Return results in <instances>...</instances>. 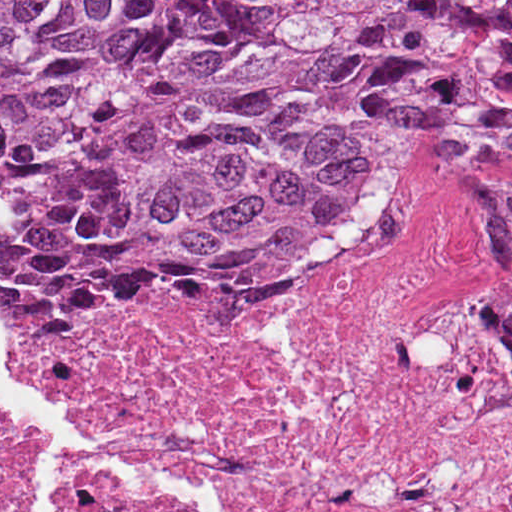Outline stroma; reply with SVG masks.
Here are the masks:
<instances>
[{
    "label": "stroma",
    "instance_id": "35a3bbf8",
    "mask_svg": "<svg viewBox=\"0 0 512 512\" xmlns=\"http://www.w3.org/2000/svg\"><path fill=\"white\" fill-rule=\"evenodd\" d=\"M468 153H512V123L491 120L448 123L427 136L391 184L415 167L438 158ZM389 186L364 216V245L319 289L383 268L372 238ZM494 287L512 346V202L494 229ZM281 295L284 294H240L211 288L164 294L141 305L114 310H76L37 299H0V359L15 367L12 345L37 327L114 311H213L263 302ZM0 442L22 441L0 425Z\"/></svg>",
    "mask_w": 512,
    "mask_h": 512
}]
</instances>
